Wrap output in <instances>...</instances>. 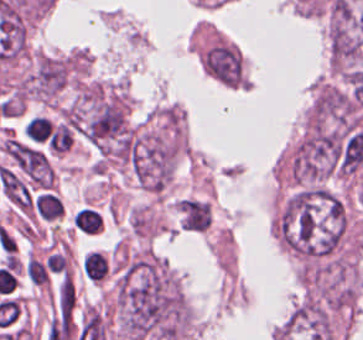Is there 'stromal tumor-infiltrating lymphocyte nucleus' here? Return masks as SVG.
<instances>
[{"label": "stromal tumor-infiltrating lymphocyte nucleus", "mask_w": 363, "mask_h": 340, "mask_svg": "<svg viewBox=\"0 0 363 340\" xmlns=\"http://www.w3.org/2000/svg\"><path fill=\"white\" fill-rule=\"evenodd\" d=\"M33 217L55 223L63 214V204L55 190H35L31 203Z\"/></svg>", "instance_id": "1"}, {"label": "stromal tumor-infiltrating lymphocyte nucleus", "mask_w": 363, "mask_h": 340, "mask_svg": "<svg viewBox=\"0 0 363 340\" xmlns=\"http://www.w3.org/2000/svg\"><path fill=\"white\" fill-rule=\"evenodd\" d=\"M109 267V260L102 250L89 249L81 262L85 278L95 284L106 279Z\"/></svg>", "instance_id": "2"}, {"label": "stromal tumor-infiltrating lymphocyte nucleus", "mask_w": 363, "mask_h": 340, "mask_svg": "<svg viewBox=\"0 0 363 340\" xmlns=\"http://www.w3.org/2000/svg\"><path fill=\"white\" fill-rule=\"evenodd\" d=\"M73 229L76 232L96 235L102 232L101 213L91 206H84L73 216Z\"/></svg>", "instance_id": "3"}, {"label": "stromal tumor-infiltrating lymphocyte nucleus", "mask_w": 363, "mask_h": 340, "mask_svg": "<svg viewBox=\"0 0 363 340\" xmlns=\"http://www.w3.org/2000/svg\"><path fill=\"white\" fill-rule=\"evenodd\" d=\"M27 272L34 284L48 285L49 274L46 267L36 260L32 255L27 263Z\"/></svg>", "instance_id": "4"}]
</instances>
